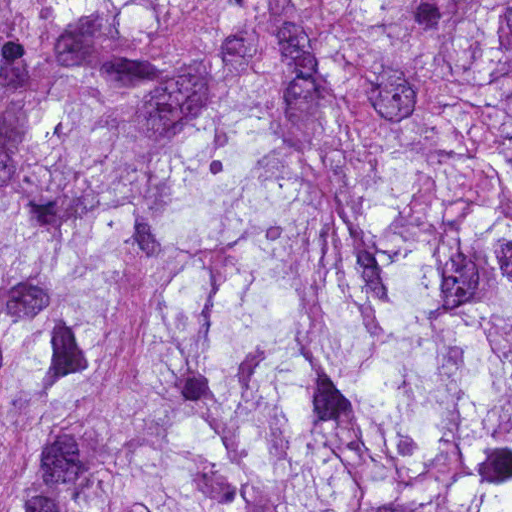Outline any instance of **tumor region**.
<instances>
[{
    "mask_svg": "<svg viewBox=\"0 0 512 512\" xmlns=\"http://www.w3.org/2000/svg\"><path fill=\"white\" fill-rule=\"evenodd\" d=\"M1 512H512V1H1Z\"/></svg>",
    "mask_w": 512,
    "mask_h": 512,
    "instance_id": "e687c5a6",
    "label": "tumor region"
}]
</instances>
